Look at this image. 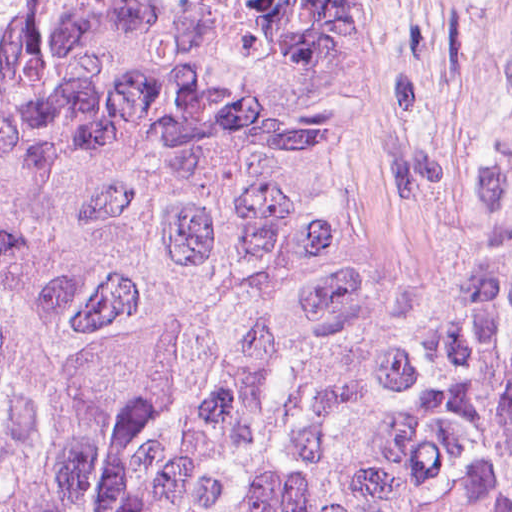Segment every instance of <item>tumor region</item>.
I'll list each match as a JSON object with an SVG mask.
<instances>
[{
    "label": "tumor region",
    "mask_w": 512,
    "mask_h": 512,
    "mask_svg": "<svg viewBox=\"0 0 512 512\" xmlns=\"http://www.w3.org/2000/svg\"><path fill=\"white\" fill-rule=\"evenodd\" d=\"M310 53L275 0H0V512H512V115L405 278Z\"/></svg>",
    "instance_id": "e687c5a6"
}]
</instances>
